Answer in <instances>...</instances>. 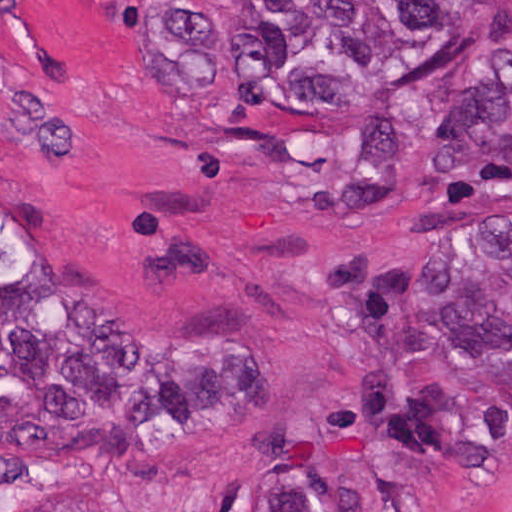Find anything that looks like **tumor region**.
Segmentation results:
<instances>
[{
  "instance_id": "tumor-region-1",
  "label": "tumor region",
  "mask_w": 512,
  "mask_h": 512,
  "mask_svg": "<svg viewBox=\"0 0 512 512\" xmlns=\"http://www.w3.org/2000/svg\"><path fill=\"white\" fill-rule=\"evenodd\" d=\"M476 7L512 0H204L244 103L356 112L388 97ZM450 344L512 374V228L451 229L426 304ZM453 448L447 401L388 406L330 512H432Z\"/></svg>"
}]
</instances>
